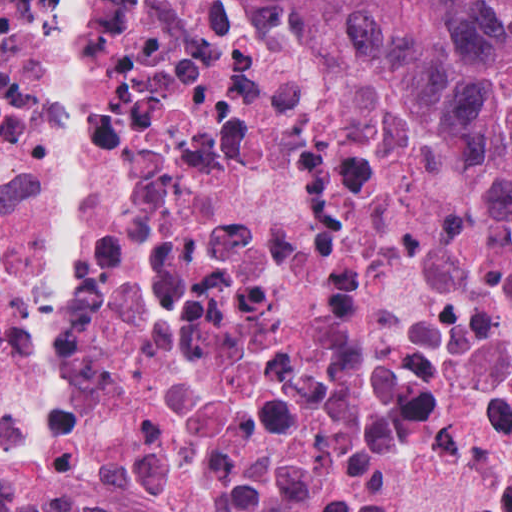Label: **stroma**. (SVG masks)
<instances>
[{
    "mask_svg": "<svg viewBox=\"0 0 512 512\" xmlns=\"http://www.w3.org/2000/svg\"><path fill=\"white\" fill-rule=\"evenodd\" d=\"M447 94L462 125L471 138L479 177L480 124L448 92Z\"/></svg>",
    "mask_w": 512,
    "mask_h": 512,
    "instance_id": "obj_1",
    "label": "stroma"
}]
</instances>
